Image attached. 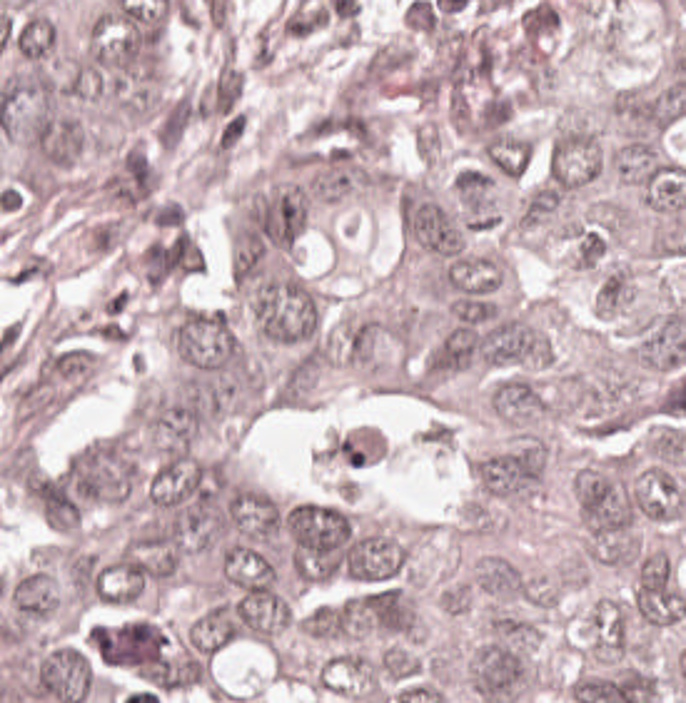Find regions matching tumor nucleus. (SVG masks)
Masks as SVG:
<instances>
[{"mask_svg": "<svg viewBox=\"0 0 686 703\" xmlns=\"http://www.w3.org/2000/svg\"><path fill=\"white\" fill-rule=\"evenodd\" d=\"M249 304L262 342L301 357L317 349L322 310L293 271L274 269L253 287Z\"/></svg>", "mask_w": 686, "mask_h": 703, "instance_id": "obj_1", "label": "tumor nucleus"}, {"mask_svg": "<svg viewBox=\"0 0 686 703\" xmlns=\"http://www.w3.org/2000/svg\"><path fill=\"white\" fill-rule=\"evenodd\" d=\"M167 342L189 372H223L240 355L230 318L208 306H182L167 328Z\"/></svg>", "mask_w": 686, "mask_h": 703, "instance_id": "obj_2", "label": "tumor nucleus"}, {"mask_svg": "<svg viewBox=\"0 0 686 703\" xmlns=\"http://www.w3.org/2000/svg\"><path fill=\"white\" fill-rule=\"evenodd\" d=\"M396 212L404 235L424 250L446 260L462 252L465 216L452 201L406 181Z\"/></svg>", "mask_w": 686, "mask_h": 703, "instance_id": "obj_3", "label": "tumor nucleus"}, {"mask_svg": "<svg viewBox=\"0 0 686 703\" xmlns=\"http://www.w3.org/2000/svg\"><path fill=\"white\" fill-rule=\"evenodd\" d=\"M580 517L596 539L615 541L631 526L639 493L610 465L576 471Z\"/></svg>", "mask_w": 686, "mask_h": 703, "instance_id": "obj_4", "label": "tumor nucleus"}, {"mask_svg": "<svg viewBox=\"0 0 686 703\" xmlns=\"http://www.w3.org/2000/svg\"><path fill=\"white\" fill-rule=\"evenodd\" d=\"M628 605L636 619L662 626L686 610V593L667 561L643 556L632 571Z\"/></svg>", "mask_w": 686, "mask_h": 703, "instance_id": "obj_5", "label": "tumor nucleus"}, {"mask_svg": "<svg viewBox=\"0 0 686 703\" xmlns=\"http://www.w3.org/2000/svg\"><path fill=\"white\" fill-rule=\"evenodd\" d=\"M527 656L519 640L496 635L478 654L472 672L479 703H511L526 675Z\"/></svg>", "mask_w": 686, "mask_h": 703, "instance_id": "obj_6", "label": "tumor nucleus"}, {"mask_svg": "<svg viewBox=\"0 0 686 703\" xmlns=\"http://www.w3.org/2000/svg\"><path fill=\"white\" fill-rule=\"evenodd\" d=\"M481 487L491 494H522L542 472L540 446H514L476 466Z\"/></svg>", "mask_w": 686, "mask_h": 703, "instance_id": "obj_7", "label": "tumor nucleus"}]
</instances>
